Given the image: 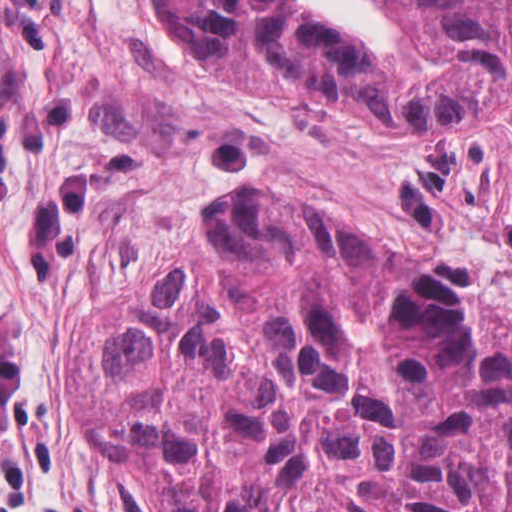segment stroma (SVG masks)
Returning a JSON list of instances; mask_svg holds the SVG:
<instances>
[{"label":"stroma","instance_id":"obj_1","mask_svg":"<svg viewBox=\"0 0 512 512\" xmlns=\"http://www.w3.org/2000/svg\"><path fill=\"white\" fill-rule=\"evenodd\" d=\"M392 58L379 0H301ZM261 187L459 272L512 370V87L434 128L332 121L213 68L155 0H0V512H150L74 433V323L200 213Z\"/></svg>","mask_w":512,"mask_h":512}]
</instances>
